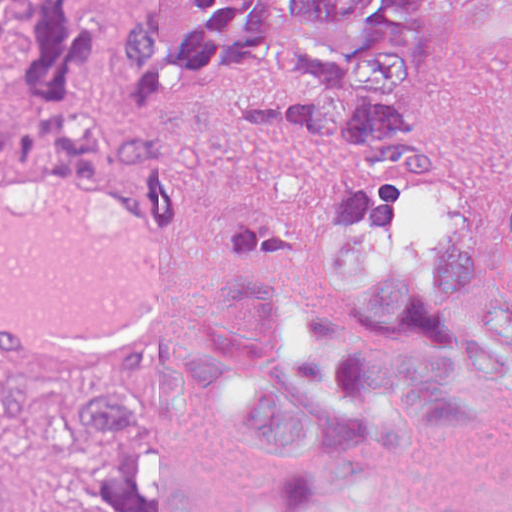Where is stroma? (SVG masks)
I'll list each match as a JSON object with an SVG mask.
<instances>
[{
	"label": "stroma",
	"instance_id": "35a3bbf8",
	"mask_svg": "<svg viewBox=\"0 0 512 512\" xmlns=\"http://www.w3.org/2000/svg\"><path fill=\"white\" fill-rule=\"evenodd\" d=\"M128 0H93V25L103 27V48L87 81L113 92L127 63L122 17ZM437 0L435 75L423 117L441 163L438 181L361 178L343 152L285 133L247 125L230 101L190 124L158 131L103 130L111 156L103 173H142L163 186L201 226L209 253V309L200 320L158 344L174 353L216 318L252 261L272 238L318 206L367 197H449L512 194V56L453 42L446 7ZM235 98H290L269 79ZM20 96L0 89V115ZM19 161L0 177L27 174ZM95 364L49 376H5L63 386ZM0 493L16 512H81L38 486L11 460L0 461Z\"/></svg>",
	"mask_w": 512,
	"mask_h": 512
}]
</instances>
